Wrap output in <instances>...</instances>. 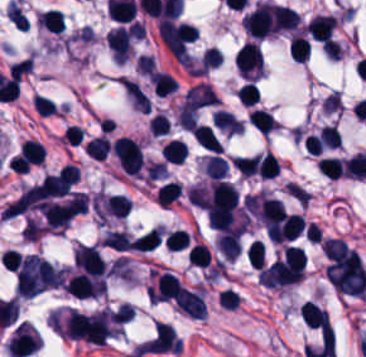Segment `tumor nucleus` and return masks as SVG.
I'll return each mask as SVG.
<instances>
[{
  "mask_svg": "<svg viewBox=\"0 0 366 357\" xmlns=\"http://www.w3.org/2000/svg\"><path fill=\"white\" fill-rule=\"evenodd\" d=\"M32 63L30 59H23L18 62L12 63L8 68V74L14 80H21L31 69Z\"/></svg>",
  "mask_w": 366,
  "mask_h": 357,
  "instance_id": "2f306a5c",
  "label": "tumor nucleus"
}]
</instances>
